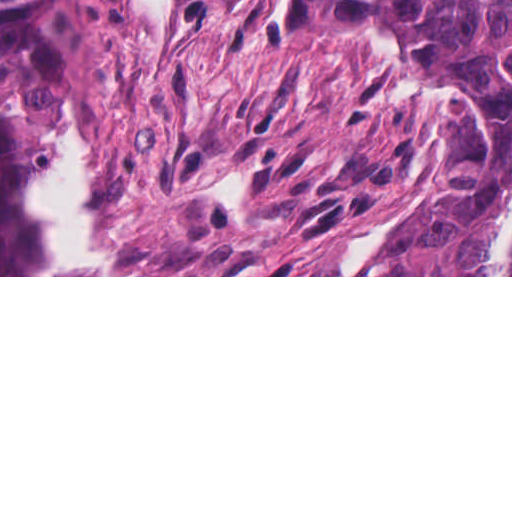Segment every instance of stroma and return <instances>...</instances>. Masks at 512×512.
<instances>
[{"mask_svg": "<svg viewBox=\"0 0 512 512\" xmlns=\"http://www.w3.org/2000/svg\"><path fill=\"white\" fill-rule=\"evenodd\" d=\"M44 123L88 120L106 275H367L457 183L500 163L482 63L360 30L309 0H0ZM377 258H338L408 204Z\"/></svg>", "mask_w": 512, "mask_h": 512, "instance_id": "35a3bbf8", "label": "stroma"}]
</instances>
